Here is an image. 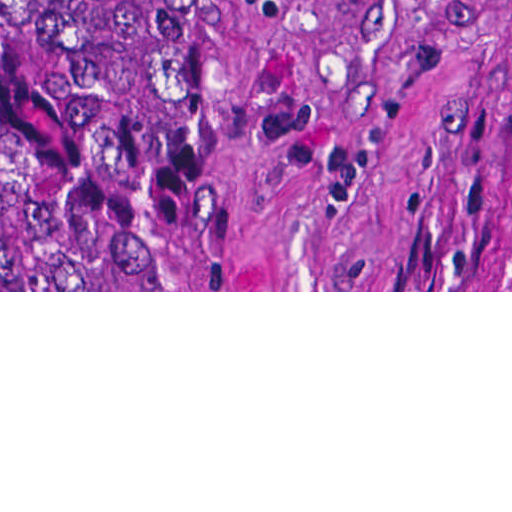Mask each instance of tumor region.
<instances>
[{
	"mask_svg": "<svg viewBox=\"0 0 512 512\" xmlns=\"http://www.w3.org/2000/svg\"><path fill=\"white\" fill-rule=\"evenodd\" d=\"M0 113H188V0H0Z\"/></svg>",
	"mask_w": 512,
	"mask_h": 512,
	"instance_id": "tumor-region-1",
	"label": "tumor region"
}]
</instances>
